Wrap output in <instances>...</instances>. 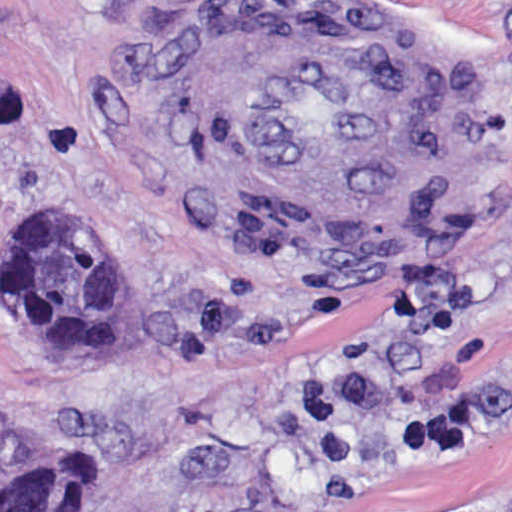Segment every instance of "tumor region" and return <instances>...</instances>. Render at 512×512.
<instances>
[{"instance_id":"1","label":"tumor region","mask_w":512,"mask_h":512,"mask_svg":"<svg viewBox=\"0 0 512 512\" xmlns=\"http://www.w3.org/2000/svg\"><path fill=\"white\" fill-rule=\"evenodd\" d=\"M17 328L54 359H105L122 335V289L106 235L64 205L17 220L1 274ZM100 464L60 437L0 453V512H93Z\"/></svg>"}]
</instances>
